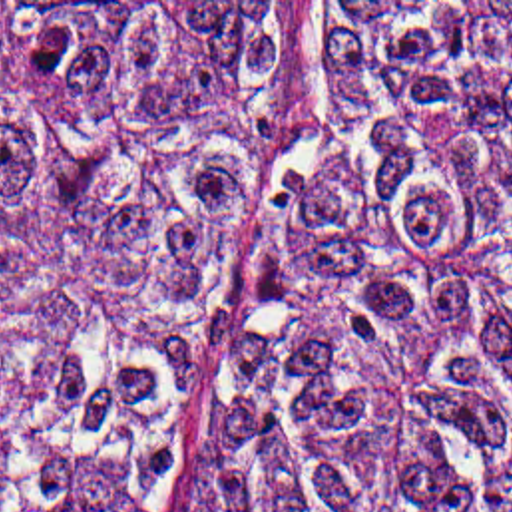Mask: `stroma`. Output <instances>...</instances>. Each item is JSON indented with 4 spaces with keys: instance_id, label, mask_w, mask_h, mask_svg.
I'll return each instance as SVG.
<instances>
[{
    "instance_id": "obj_1",
    "label": "stroma",
    "mask_w": 512,
    "mask_h": 512,
    "mask_svg": "<svg viewBox=\"0 0 512 512\" xmlns=\"http://www.w3.org/2000/svg\"><path fill=\"white\" fill-rule=\"evenodd\" d=\"M0 2H288L284 88L274 121L244 177V223L234 239L228 285L210 345L194 376L168 396L156 420V488L148 512H170L196 484L228 428V392L246 295L278 225L292 177L308 149L328 66L330 2H512V0H0Z\"/></svg>"
}]
</instances>
